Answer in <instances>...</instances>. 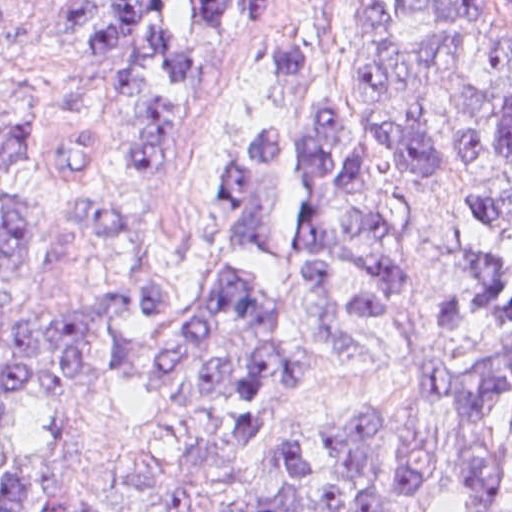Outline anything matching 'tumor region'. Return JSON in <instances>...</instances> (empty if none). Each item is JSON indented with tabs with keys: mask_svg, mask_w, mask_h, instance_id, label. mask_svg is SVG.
<instances>
[{
	"mask_svg": "<svg viewBox=\"0 0 512 512\" xmlns=\"http://www.w3.org/2000/svg\"><path fill=\"white\" fill-rule=\"evenodd\" d=\"M8 1H0L2 12ZM62 30L96 54L130 104L141 180L177 163L203 121L200 68L147 41L116 1H58ZM31 156L28 117L0 105V176ZM69 170L109 181L73 216L123 274L112 304L20 308L42 216L0 183V412L36 400L54 435L0 461V512H194L253 449L291 380L371 357L359 327L387 311L405 273L407 217L397 184L447 180L464 213L444 332L497 328L467 371L420 373L416 390L449 428L460 512L512 459V1H322L274 27L232 113L228 171L236 215L193 266L122 201L124 166L93 136L70 139ZM120 384L164 416V440L130 470L138 509H111L67 486L88 443L79 398ZM338 478L322 512H384L428 483L437 454L405 449L379 413L326 429ZM317 472L290 439L257 494L229 512H308Z\"/></svg>",
	"mask_w": 512,
	"mask_h": 512,
	"instance_id": "e687c5a6",
	"label": "tumor region"
}]
</instances>
